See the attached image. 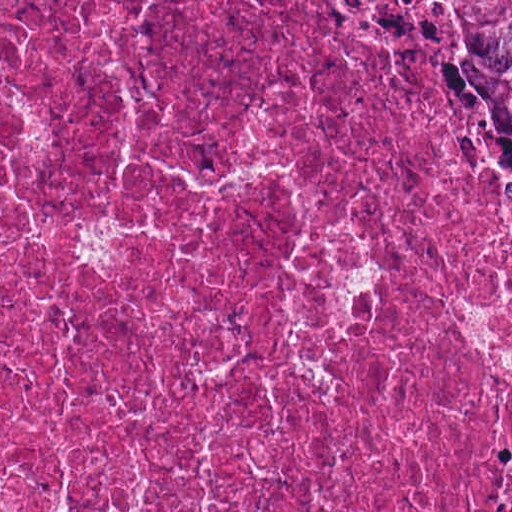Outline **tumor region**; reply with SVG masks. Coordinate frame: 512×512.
Segmentation results:
<instances>
[{
  "instance_id": "1",
  "label": "tumor region",
  "mask_w": 512,
  "mask_h": 512,
  "mask_svg": "<svg viewBox=\"0 0 512 512\" xmlns=\"http://www.w3.org/2000/svg\"><path fill=\"white\" fill-rule=\"evenodd\" d=\"M396 31L469 173L512 229V0H364Z\"/></svg>"
}]
</instances>
